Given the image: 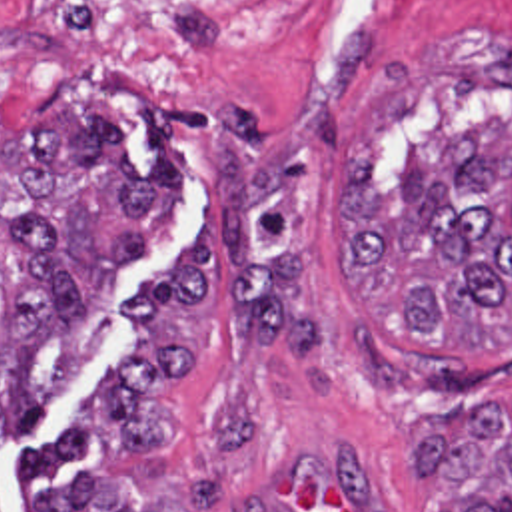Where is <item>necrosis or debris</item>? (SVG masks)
Returning a JSON list of instances; mask_svg holds the SVG:
<instances>
[{
    "instance_id": "obj_1",
    "label": "necrosis or debris",
    "mask_w": 512,
    "mask_h": 512,
    "mask_svg": "<svg viewBox=\"0 0 512 512\" xmlns=\"http://www.w3.org/2000/svg\"><path fill=\"white\" fill-rule=\"evenodd\" d=\"M276 0H0V33L50 45L106 91L188 95L250 51Z\"/></svg>"
}]
</instances>
